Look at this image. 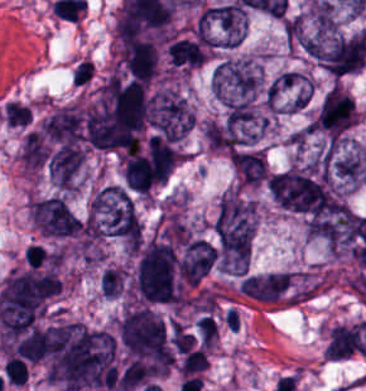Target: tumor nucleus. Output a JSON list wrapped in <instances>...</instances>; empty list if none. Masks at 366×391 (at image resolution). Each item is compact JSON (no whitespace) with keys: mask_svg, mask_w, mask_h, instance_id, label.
Wrapping results in <instances>:
<instances>
[{"mask_svg":"<svg viewBox=\"0 0 366 391\" xmlns=\"http://www.w3.org/2000/svg\"><path fill=\"white\" fill-rule=\"evenodd\" d=\"M87 221L102 238L128 244L141 239V226L130 194L119 184L99 186L86 211Z\"/></svg>","mask_w":366,"mask_h":391,"instance_id":"tumor-nucleus-1","label":"tumor nucleus"},{"mask_svg":"<svg viewBox=\"0 0 366 391\" xmlns=\"http://www.w3.org/2000/svg\"><path fill=\"white\" fill-rule=\"evenodd\" d=\"M255 228L254 208L247 203H221L214 232L221 271L246 272Z\"/></svg>","mask_w":366,"mask_h":391,"instance_id":"tumor-nucleus-2","label":"tumor nucleus"},{"mask_svg":"<svg viewBox=\"0 0 366 391\" xmlns=\"http://www.w3.org/2000/svg\"><path fill=\"white\" fill-rule=\"evenodd\" d=\"M264 84L255 60H222L210 78V90L224 112L249 108L255 103Z\"/></svg>","mask_w":366,"mask_h":391,"instance_id":"tumor-nucleus-3","label":"tumor nucleus"},{"mask_svg":"<svg viewBox=\"0 0 366 391\" xmlns=\"http://www.w3.org/2000/svg\"><path fill=\"white\" fill-rule=\"evenodd\" d=\"M198 19L214 50L234 46L246 32V10L234 2L211 5Z\"/></svg>","mask_w":366,"mask_h":391,"instance_id":"tumor-nucleus-4","label":"tumor nucleus"},{"mask_svg":"<svg viewBox=\"0 0 366 391\" xmlns=\"http://www.w3.org/2000/svg\"><path fill=\"white\" fill-rule=\"evenodd\" d=\"M149 118L163 136L179 139L192 123V109L187 99L174 88H161L149 106Z\"/></svg>","mask_w":366,"mask_h":391,"instance_id":"tumor-nucleus-5","label":"tumor nucleus"},{"mask_svg":"<svg viewBox=\"0 0 366 391\" xmlns=\"http://www.w3.org/2000/svg\"><path fill=\"white\" fill-rule=\"evenodd\" d=\"M28 215L33 227L44 235L68 237L79 232L78 222L56 196L29 202Z\"/></svg>","mask_w":366,"mask_h":391,"instance_id":"tumor-nucleus-6","label":"tumor nucleus"},{"mask_svg":"<svg viewBox=\"0 0 366 391\" xmlns=\"http://www.w3.org/2000/svg\"><path fill=\"white\" fill-rule=\"evenodd\" d=\"M311 91L312 84L303 75L288 70L269 80L265 104L272 109L298 110Z\"/></svg>","mask_w":366,"mask_h":391,"instance_id":"tumor-nucleus-7","label":"tumor nucleus"},{"mask_svg":"<svg viewBox=\"0 0 366 391\" xmlns=\"http://www.w3.org/2000/svg\"><path fill=\"white\" fill-rule=\"evenodd\" d=\"M238 185L263 186L268 176V161L261 148H241L230 157Z\"/></svg>","mask_w":366,"mask_h":391,"instance_id":"tumor-nucleus-8","label":"tumor nucleus"},{"mask_svg":"<svg viewBox=\"0 0 366 391\" xmlns=\"http://www.w3.org/2000/svg\"><path fill=\"white\" fill-rule=\"evenodd\" d=\"M248 295L254 301L276 303L293 295L288 272L272 271L248 275Z\"/></svg>","mask_w":366,"mask_h":391,"instance_id":"tumor-nucleus-9","label":"tumor nucleus"},{"mask_svg":"<svg viewBox=\"0 0 366 391\" xmlns=\"http://www.w3.org/2000/svg\"><path fill=\"white\" fill-rule=\"evenodd\" d=\"M360 351L359 326L355 324H339L332 326L329 332L325 360L347 358Z\"/></svg>","mask_w":366,"mask_h":391,"instance_id":"tumor-nucleus-10","label":"tumor nucleus"},{"mask_svg":"<svg viewBox=\"0 0 366 391\" xmlns=\"http://www.w3.org/2000/svg\"><path fill=\"white\" fill-rule=\"evenodd\" d=\"M167 51L171 66L193 69L208 57L199 43L193 40H173Z\"/></svg>","mask_w":366,"mask_h":391,"instance_id":"tumor-nucleus-11","label":"tumor nucleus"},{"mask_svg":"<svg viewBox=\"0 0 366 391\" xmlns=\"http://www.w3.org/2000/svg\"><path fill=\"white\" fill-rule=\"evenodd\" d=\"M126 273L120 266H106L99 276V291L104 297H117L125 290Z\"/></svg>","mask_w":366,"mask_h":391,"instance_id":"tumor-nucleus-12","label":"tumor nucleus"}]
</instances>
